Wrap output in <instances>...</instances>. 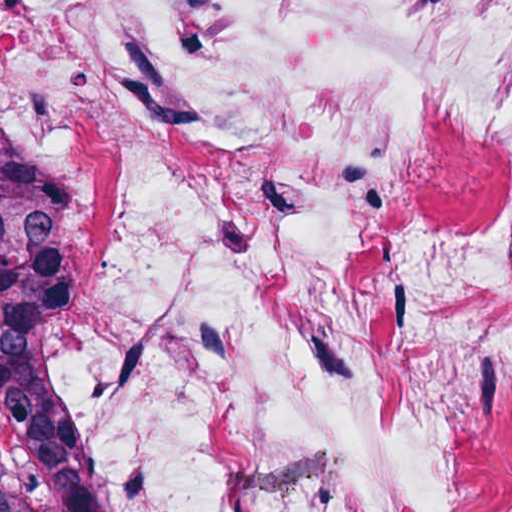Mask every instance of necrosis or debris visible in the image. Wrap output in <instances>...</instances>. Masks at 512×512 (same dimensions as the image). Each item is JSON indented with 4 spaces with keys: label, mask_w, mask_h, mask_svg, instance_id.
<instances>
[{
    "label": "necrosis or debris",
    "mask_w": 512,
    "mask_h": 512,
    "mask_svg": "<svg viewBox=\"0 0 512 512\" xmlns=\"http://www.w3.org/2000/svg\"><path fill=\"white\" fill-rule=\"evenodd\" d=\"M0 103L83 512H512V0H0Z\"/></svg>",
    "instance_id": "necrosis-or-debris-1"
}]
</instances>
